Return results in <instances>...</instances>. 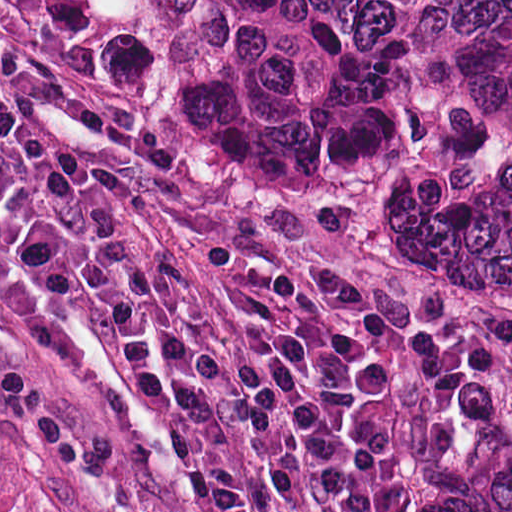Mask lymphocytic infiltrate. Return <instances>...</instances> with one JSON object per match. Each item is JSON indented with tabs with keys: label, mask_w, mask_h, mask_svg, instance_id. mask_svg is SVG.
<instances>
[{
	"label": "lymphocytic infiltrate",
	"mask_w": 512,
	"mask_h": 512,
	"mask_svg": "<svg viewBox=\"0 0 512 512\" xmlns=\"http://www.w3.org/2000/svg\"><path fill=\"white\" fill-rule=\"evenodd\" d=\"M0 248L102 349L198 512H259L216 422L260 482L311 512H380L396 442L384 403L450 373L334 266L312 283L238 243L196 244L215 293L115 215L139 182L0 90ZM234 305L239 313L228 304Z\"/></svg>",
	"instance_id": "f902f5d3"
}]
</instances>
